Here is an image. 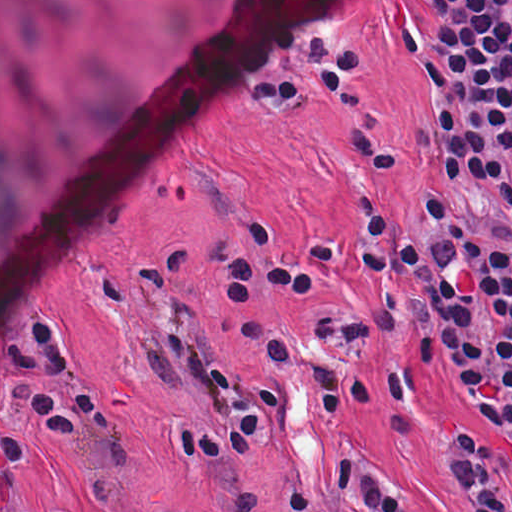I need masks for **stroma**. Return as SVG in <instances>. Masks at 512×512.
Masks as SVG:
<instances>
[{
	"label": "stroma",
	"instance_id": "35a3bbf8",
	"mask_svg": "<svg viewBox=\"0 0 512 512\" xmlns=\"http://www.w3.org/2000/svg\"><path fill=\"white\" fill-rule=\"evenodd\" d=\"M377 213L418 246L430 230L413 192L360 216ZM360 216L186 293L200 290L196 320L218 354L284 407L277 442L251 465H214L169 439L166 424L212 427L221 415L216 388L178 356L158 315V306L186 294L0 375L60 512H286L280 490L291 479L319 490L342 449L384 472L414 512H470L441 465V431L479 421L488 435L504 437L438 351L423 413L408 432L391 396L377 405L360 395L337 418L304 374L271 367L257 348L235 342L244 316L292 329L336 368L396 371L414 360L409 333L354 341L321 332L331 308L354 316L370 304L357 255ZM313 242H338L347 256L323 292L229 293L225 281L270 276L279 259Z\"/></svg>",
	"mask_w": 512,
	"mask_h": 512
}]
</instances>
